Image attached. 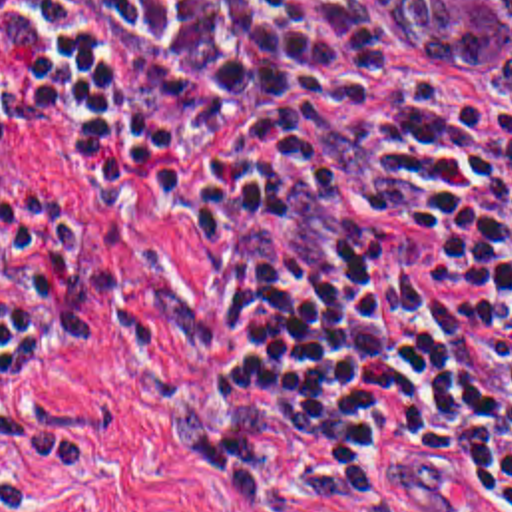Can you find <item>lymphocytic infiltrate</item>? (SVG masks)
<instances>
[{
    "instance_id": "f902f5d3",
    "label": "lymphocytic infiltrate",
    "mask_w": 512,
    "mask_h": 512,
    "mask_svg": "<svg viewBox=\"0 0 512 512\" xmlns=\"http://www.w3.org/2000/svg\"><path fill=\"white\" fill-rule=\"evenodd\" d=\"M0 31V151L4 103L97 121L203 240L195 412L239 512L512 509L510 129L340 0H0ZM54 340L38 282L0 304V439Z\"/></svg>"
}]
</instances>
